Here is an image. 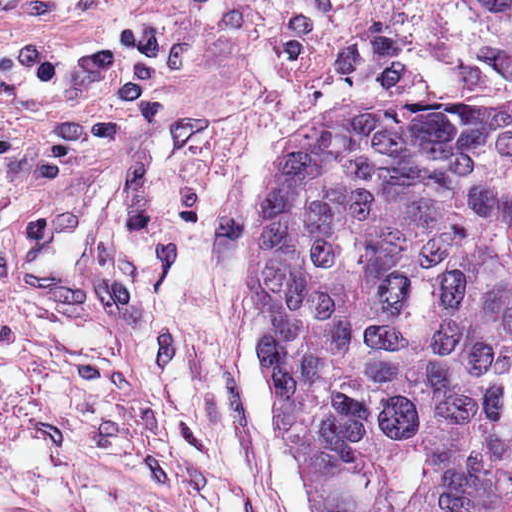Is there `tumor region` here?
<instances>
[{"label":"tumor region","mask_w":512,"mask_h":512,"mask_svg":"<svg viewBox=\"0 0 512 512\" xmlns=\"http://www.w3.org/2000/svg\"><path fill=\"white\" fill-rule=\"evenodd\" d=\"M254 293L315 512H512V95L333 97L267 198Z\"/></svg>","instance_id":"obj_1"}]
</instances>
